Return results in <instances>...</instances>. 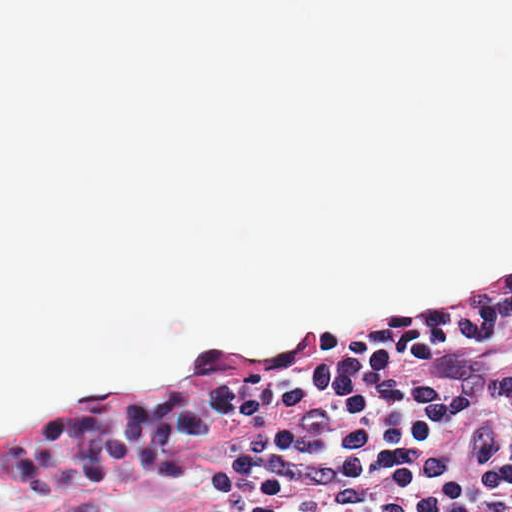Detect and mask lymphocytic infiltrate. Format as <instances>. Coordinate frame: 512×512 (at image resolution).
<instances>
[{"label": "lymphocytic infiltrate", "instance_id": "lymphocytic-infiltrate-1", "mask_svg": "<svg viewBox=\"0 0 512 512\" xmlns=\"http://www.w3.org/2000/svg\"><path fill=\"white\" fill-rule=\"evenodd\" d=\"M210 455L211 512H512V275L252 351L1 467L21 510Z\"/></svg>", "mask_w": 512, "mask_h": 512}]
</instances>
